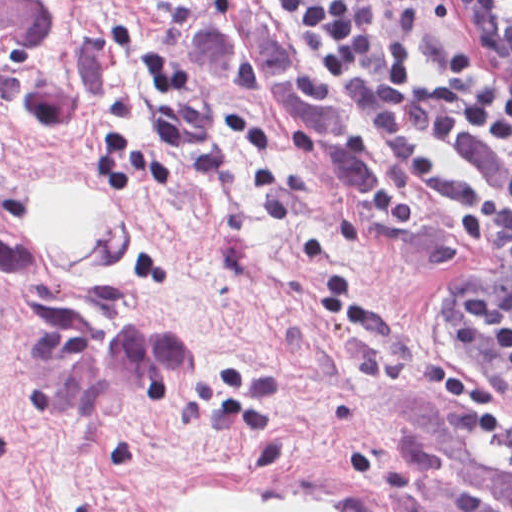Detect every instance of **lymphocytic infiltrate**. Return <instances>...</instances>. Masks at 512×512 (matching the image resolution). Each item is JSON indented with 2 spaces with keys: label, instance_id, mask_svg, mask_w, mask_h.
Listing matches in <instances>:
<instances>
[{
  "label": "lymphocytic infiltrate",
  "instance_id": "1",
  "mask_svg": "<svg viewBox=\"0 0 512 512\" xmlns=\"http://www.w3.org/2000/svg\"><path fill=\"white\" fill-rule=\"evenodd\" d=\"M271 2L386 144L389 179L369 205L375 222L400 230L424 204L454 217L467 254L490 253L486 274L447 309L457 365L429 361L425 385L448 410L512 425L511 78L456 43L416 59L413 0ZM441 3L465 32L512 33V0Z\"/></svg>",
  "mask_w": 512,
  "mask_h": 512
}]
</instances>
